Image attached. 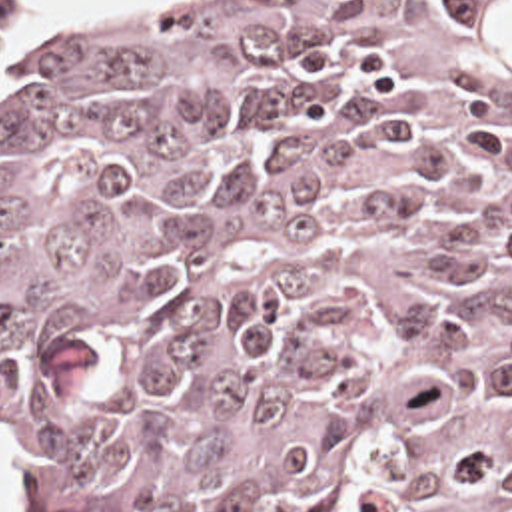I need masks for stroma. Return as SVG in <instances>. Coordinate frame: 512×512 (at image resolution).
<instances>
[{"instance_id":"35a3bbf8","label":"stroma","mask_w":512,"mask_h":512,"mask_svg":"<svg viewBox=\"0 0 512 512\" xmlns=\"http://www.w3.org/2000/svg\"><path fill=\"white\" fill-rule=\"evenodd\" d=\"M105 2H113V0H63V2H51V4H31L27 0H0V28H5L13 22L45 18V16L57 14L61 10H67V8L93 6V4H105ZM0 460L5 466H9L21 480V495H23L29 511L47 512L45 499H43L35 472H31L27 466H23L19 460H15L11 454H7L1 448Z\"/></svg>"}]
</instances>
